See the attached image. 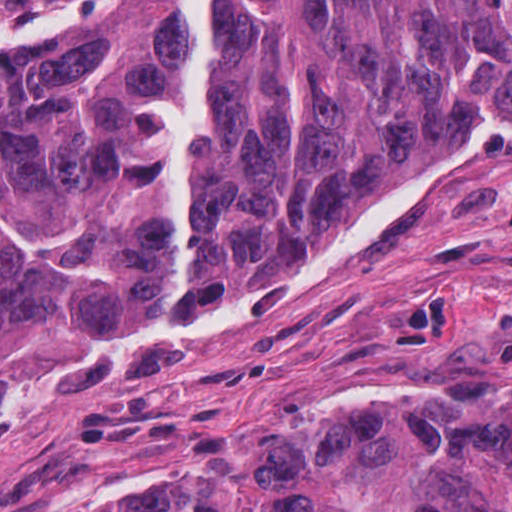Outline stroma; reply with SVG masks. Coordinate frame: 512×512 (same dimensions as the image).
I'll return each instance as SVG.
<instances>
[{"label": "stroma", "mask_w": 512, "mask_h": 512, "mask_svg": "<svg viewBox=\"0 0 512 512\" xmlns=\"http://www.w3.org/2000/svg\"><path fill=\"white\" fill-rule=\"evenodd\" d=\"M271 306L176 325L43 391L137 369ZM477 396L512 401V216L482 274L279 304L0 432V512H122L194 451L324 406Z\"/></svg>", "instance_id": "obj_1"}]
</instances>
